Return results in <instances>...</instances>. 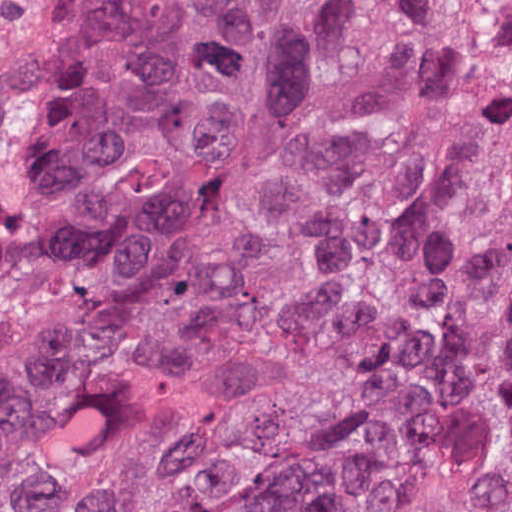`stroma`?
<instances>
[{
    "label": "stroma",
    "mask_w": 512,
    "mask_h": 512,
    "mask_svg": "<svg viewBox=\"0 0 512 512\" xmlns=\"http://www.w3.org/2000/svg\"><path fill=\"white\" fill-rule=\"evenodd\" d=\"M87 0H0V98L21 82Z\"/></svg>",
    "instance_id": "1"
}]
</instances>
